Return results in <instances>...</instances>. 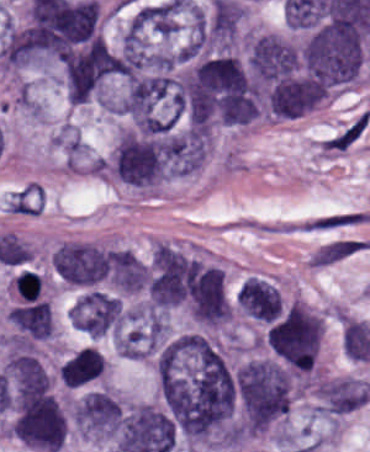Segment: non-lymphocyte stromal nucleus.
Returning a JSON list of instances; mask_svg holds the SVG:
<instances>
[{"instance_id": "dd21d789", "label": "non-lymphocyte stromal nucleus", "mask_w": 370, "mask_h": 452, "mask_svg": "<svg viewBox=\"0 0 370 452\" xmlns=\"http://www.w3.org/2000/svg\"><path fill=\"white\" fill-rule=\"evenodd\" d=\"M370 115L365 109L332 132L318 143L317 149L322 155L337 156L355 146L369 128Z\"/></svg>"}, {"instance_id": "a72fc3eb", "label": "non-lymphocyte stromal nucleus", "mask_w": 370, "mask_h": 452, "mask_svg": "<svg viewBox=\"0 0 370 452\" xmlns=\"http://www.w3.org/2000/svg\"><path fill=\"white\" fill-rule=\"evenodd\" d=\"M369 240L337 237L317 247L310 255L307 265L325 268L359 253L369 250Z\"/></svg>"}, {"instance_id": "3746e769", "label": "non-lymphocyte stromal nucleus", "mask_w": 370, "mask_h": 452, "mask_svg": "<svg viewBox=\"0 0 370 452\" xmlns=\"http://www.w3.org/2000/svg\"><path fill=\"white\" fill-rule=\"evenodd\" d=\"M360 219V210H334L311 216L297 226L306 232H325L354 226Z\"/></svg>"}, {"instance_id": "fc2b8d12", "label": "non-lymphocyte stromal nucleus", "mask_w": 370, "mask_h": 452, "mask_svg": "<svg viewBox=\"0 0 370 452\" xmlns=\"http://www.w3.org/2000/svg\"><path fill=\"white\" fill-rule=\"evenodd\" d=\"M260 232L303 233L301 221H275L258 225Z\"/></svg>"}]
</instances>
